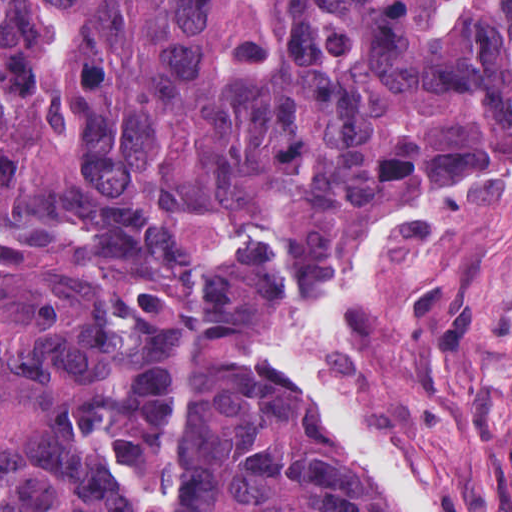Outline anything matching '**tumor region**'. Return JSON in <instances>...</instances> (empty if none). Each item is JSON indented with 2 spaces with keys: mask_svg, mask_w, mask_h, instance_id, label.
Masks as SVG:
<instances>
[{
  "mask_svg": "<svg viewBox=\"0 0 512 512\" xmlns=\"http://www.w3.org/2000/svg\"><path fill=\"white\" fill-rule=\"evenodd\" d=\"M512 139V0H0V512H371L218 326Z\"/></svg>",
  "mask_w": 512,
  "mask_h": 512,
  "instance_id": "1",
  "label": "tumor region"
}]
</instances>
